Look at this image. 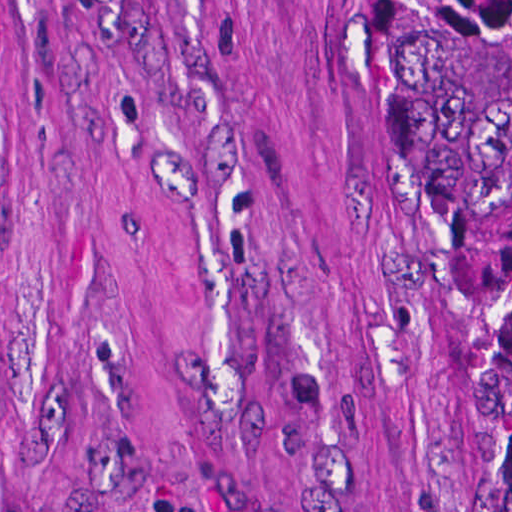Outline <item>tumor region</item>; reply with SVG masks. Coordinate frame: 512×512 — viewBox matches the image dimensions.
Listing matches in <instances>:
<instances>
[{
  "mask_svg": "<svg viewBox=\"0 0 512 512\" xmlns=\"http://www.w3.org/2000/svg\"><path fill=\"white\" fill-rule=\"evenodd\" d=\"M376 4L402 121L434 177L465 299L480 512H512V0ZM139 512L181 510L141 493Z\"/></svg>",
  "mask_w": 512,
  "mask_h": 512,
  "instance_id": "tumor-region-1",
  "label": "tumor region"
}]
</instances>
